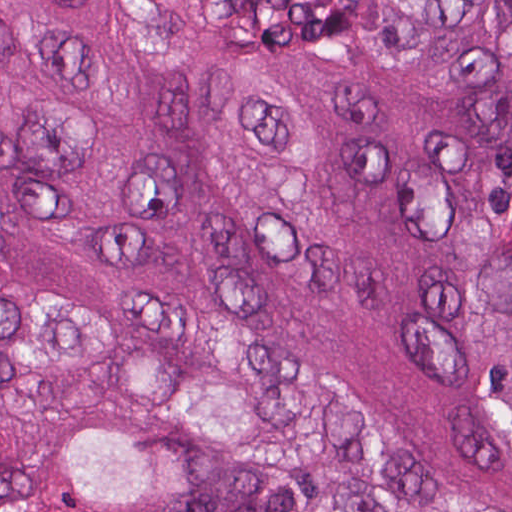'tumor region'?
Masks as SVG:
<instances>
[{"instance_id": "e687c5a6", "label": "tumor region", "mask_w": 512, "mask_h": 512, "mask_svg": "<svg viewBox=\"0 0 512 512\" xmlns=\"http://www.w3.org/2000/svg\"><path fill=\"white\" fill-rule=\"evenodd\" d=\"M0 512H512V0H0Z\"/></svg>"}]
</instances>
